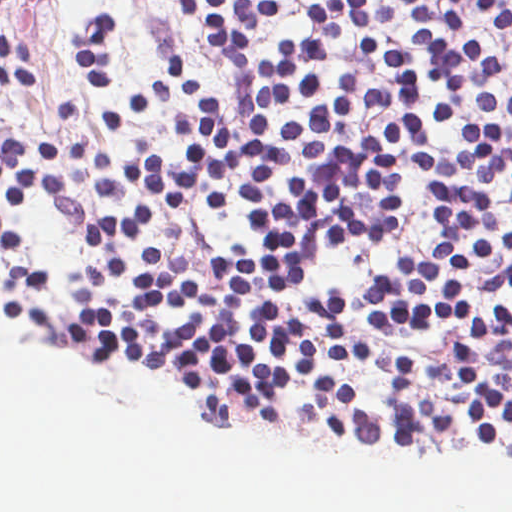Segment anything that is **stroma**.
Returning a JSON list of instances; mask_svg holds the SVG:
<instances>
[{
	"label": "stroma",
	"instance_id": "35a3bbf8",
	"mask_svg": "<svg viewBox=\"0 0 512 512\" xmlns=\"http://www.w3.org/2000/svg\"><path fill=\"white\" fill-rule=\"evenodd\" d=\"M312 0H282L270 29L252 43V51L275 55L288 39L308 33V8ZM396 11L400 34L408 40L411 13L403 0H374ZM185 0H13L0 8V35L28 43L35 54L40 81H0V132L23 140L58 144L60 155L52 162L23 147L16 155L69 177L72 185L88 190L94 156L100 148L116 162L147 152L168 162L188 144L174 134L172 122L194 118L166 79L172 61L192 64L204 89L217 104L237 105L220 65L201 32L184 14ZM106 10L116 16L112 36L114 54L110 88L99 94L76 57V42L93 12ZM443 88L429 84V127L437 156L459 153L457 135L461 122H485L504 129L512 152V116L483 111L473 105V94L464 90V111L450 127L438 126L432 117L434 94ZM410 175L399 236L377 251L351 256L334 248L322 253L320 265L367 280L387 258L434 241L438 217L430 196L432 189L404 158ZM240 238L255 240L253 219L242 211L198 206L173 216ZM469 286L479 311L489 305L512 304L487 266L474 268Z\"/></svg>",
	"mask_w": 512,
	"mask_h": 512
}]
</instances>
